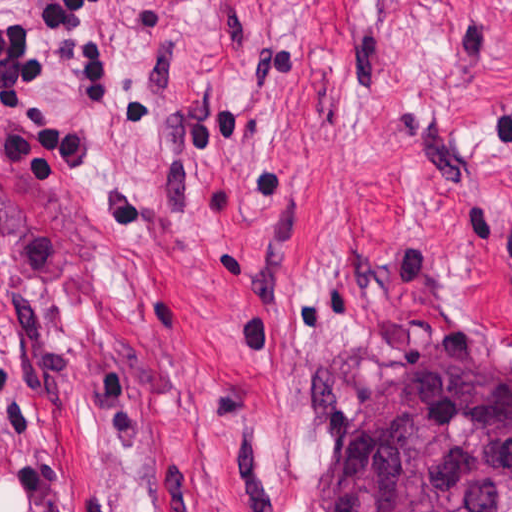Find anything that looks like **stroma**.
<instances>
[{
	"instance_id": "obj_1",
	"label": "stroma",
	"mask_w": 512,
	"mask_h": 512,
	"mask_svg": "<svg viewBox=\"0 0 512 512\" xmlns=\"http://www.w3.org/2000/svg\"><path fill=\"white\" fill-rule=\"evenodd\" d=\"M0 128V512H334L354 429L512 367V0H108L111 109Z\"/></svg>"
}]
</instances>
